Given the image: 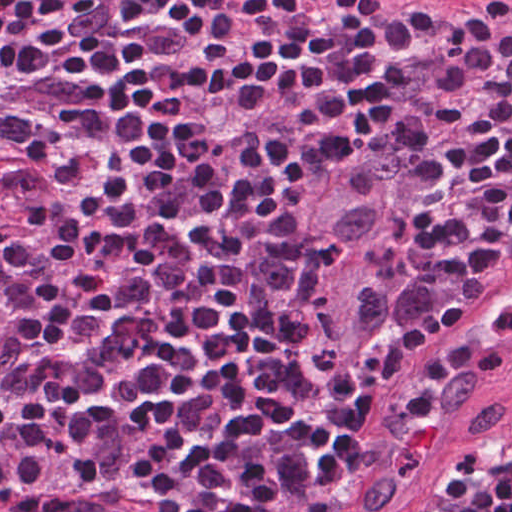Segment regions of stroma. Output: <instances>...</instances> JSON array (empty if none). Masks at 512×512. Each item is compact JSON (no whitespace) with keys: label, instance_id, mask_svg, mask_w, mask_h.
Masks as SVG:
<instances>
[{"label":"stroma","instance_id":"35a3bbf8","mask_svg":"<svg viewBox=\"0 0 512 512\" xmlns=\"http://www.w3.org/2000/svg\"><path fill=\"white\" fill-rule=\"evenodd\" d=\"M40 1L47 6L59 0ZM334 1L355 3L373 14L512 20V0ZM375 162L387 167L393 178L391 238L384 260L377 336L355 361L338 365L318 349L304 327L297 298L300 258L313 228L319 194L331 173L357 163L349 173ZM444 209L445 142L439 131L343 149L327 160L269 266L291 301L316 391H326L359 367L376 343L419 307L446 298L458 300L460 306L472 294H445L438 290L437 274L426 276V258ZM20 212L14 198L0 187V224ZM511 432L512 377L393 512H451L449 493L461 458L477 446L507 439ZM344 496L345 492L317 495V499L326 512H348Z\"/></svg>","mask_w":512,"mask_h":512}]
</instances>
